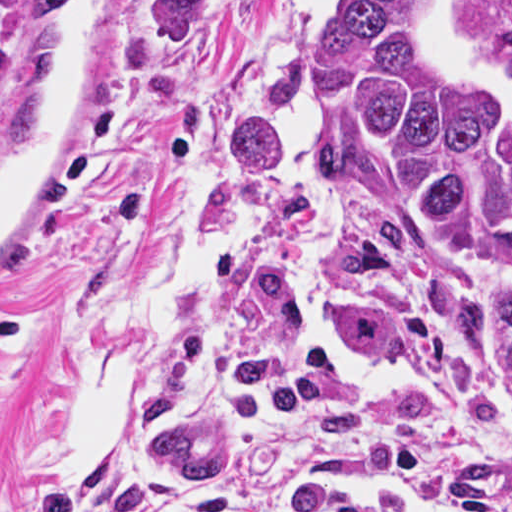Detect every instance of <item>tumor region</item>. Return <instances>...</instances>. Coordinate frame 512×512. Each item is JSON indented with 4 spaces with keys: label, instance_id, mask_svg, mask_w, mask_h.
I'll return each mask as SVG.
<instances>
[{
    "label": "tumor region",
    "instance_id": "obj_1",
    "mask_svg": "<svg viewBox=\"0 0 512 512\" xmlns=\"http://www.w3.org/2000/svg\"><path fill=\"white\" fill-rule=\"evenodd\" d=\"M235 2L163 0L153 57L193 63ZM316 65L340 175L329 337L362 357H403L408 245L429 225L452 241L463 312L512 343V34L470 60L450 46L436 0H342Z\"/></svg>",
    "mask_w": 512,
    "mask_h": 512
}]
</instances>
